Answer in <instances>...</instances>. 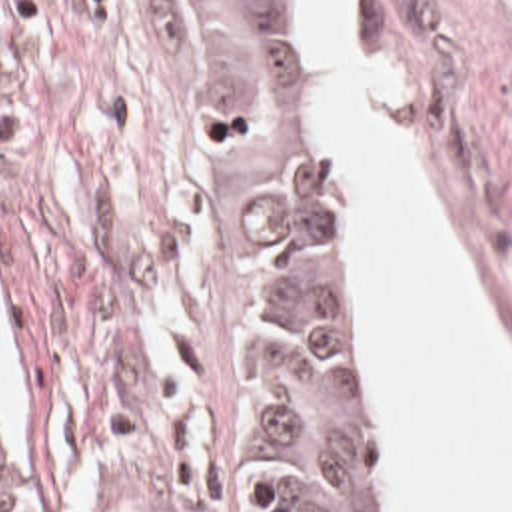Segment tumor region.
<instances>
[{"instance_id": "e687c5a6", "label": "tumor region", "mask_w": 512, "mask_h": 512, "mask_svg": "<svg viewBox=\"0 0 512 512\" xmlns=\"http://www.w3.org/2000/svg\"><path fill=\"white\" fill-rule=\"evenodd\" d=\"M155 2L227 152L239 210L257 346V479L239 512H381L303 0ZM0 512H25L1 477Z\"/></svg>"}]
</instances>
